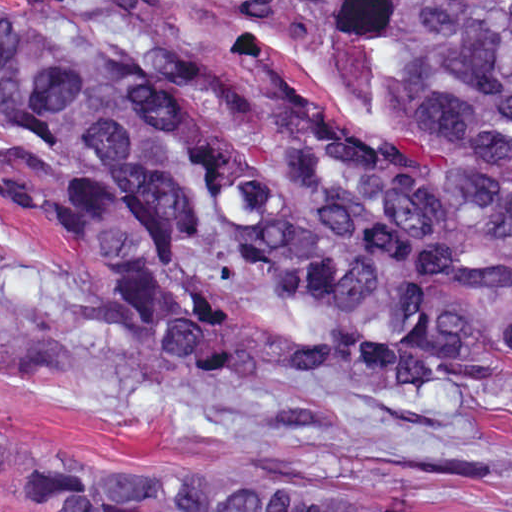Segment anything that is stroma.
<instances>
[{
  "mask_svg": "<svg viewBox=\"0 0 512 512\" xmlns=\"http://www.w3.org/2000/svg\"><path fill=\"white\" fill-rule=\"evenodd\" d=\"M0 1H146L141 21L189 60L191 97L202 110L255 125L323 112L357 145L443 160L446 147L383 110L373 69L324 21L287 12L273 29L214 1L512 0ZM42 176L21 126L0 111V267L98 283L37 188ZM483 355L488 386L462 413L413 398L277 409L235 400L188 370L58 319L0 318V425L16 451L203 445L285 454L430 484L461 512H512V413L504 412L512 359L493 345ZM30 496L10 463L0 472V512H23Z\"/></svg>",
  "mask_w": 512,
  "mask_h": 512,
  "instance_id": "35a3bbf8",
  "label": "stroma"
}]
</instances>
